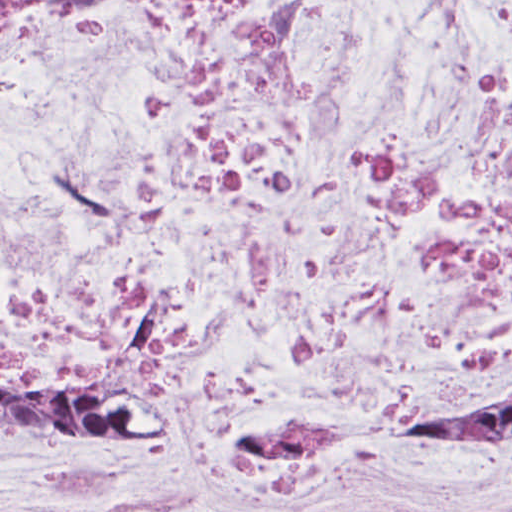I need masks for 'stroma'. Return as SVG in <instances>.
<instances>
[{
  "mask_svg": "<svg viewBox=\"0 0 512 512\" xmlns=\"http://www.w3.org/2000/svg\"><path fill=\"white\" fill-rule=\"evenodd\" d=\"M430 399L428 400H423L407 409L404 410V427H408V424H409V420H410V416L411 414L416 410L418 409L420 406H422L424 403H426L427 401H429ZM151 431H149L148 433H146L145 435H142V436H138V437H134V438H129L131 440H136V441H141V442H144V440L147 438V436L150 434Z\"/></svg>",
  "mask_w": 512,
  "mask_h": 512,
  "instance_id": "obj_1",
  "label": "stroma"
}]
</instances>
